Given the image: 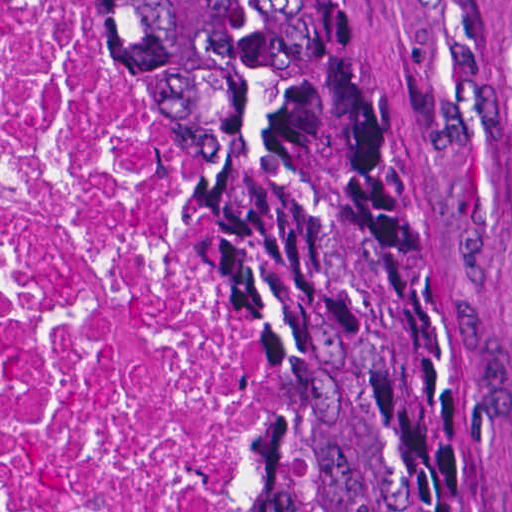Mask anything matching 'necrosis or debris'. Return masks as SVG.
<instances>
[{
	"label": "necrosis or debris",
	"instance_id": "obj_1",
	"mask_svg": "<svg viewBox=\"0 0 512 512\" xmlns=\"http://www.w3.org/2000/svg\"><path fill=\"white\" fill-rule=\"evenodd\" d=\"M0 512H236L230 288L90 0H0Z\"/></svg>",
	"mask_w": 512,
	"mask_h": 512
}]
</instances>
